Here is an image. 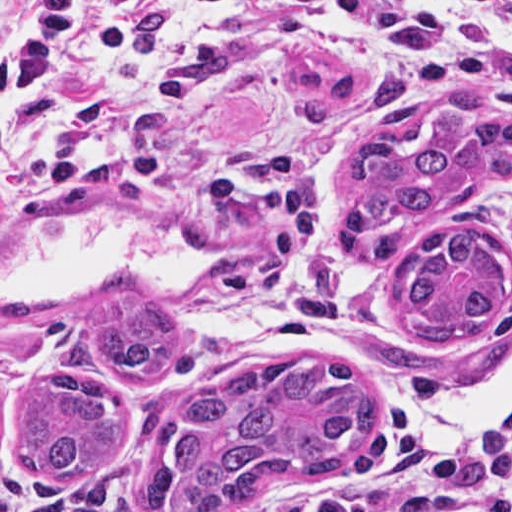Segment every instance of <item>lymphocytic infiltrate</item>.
<instances>
[{"mask_svg":"<svg viewBox=\"0 0 512 512\" xmlns=\"http://www.w3.org/2000/svg\"><path fill=\"white\" fill-rule=\"evenodd\" d=\"M460 1L512 27V2ZM249 7L312 40L351 44L391 74H440L464 94L512 102V55L411 0H25L0 29L1 89L59 99L88 92L100 33L134 76L37 166L0 165V210L52 204L84 180L170 188L200 206L261 218L290 248L315 255L329 202L313 162L276 155L251 165L218 153L170 159L147 143L148 114L192 109L227 66L214 39L176 46L168 83L150 79L149 57L193 23ZM288 512H512V409L451 415L410 401L377 428L345 483Z\"/></svg>","mask_w":512,"mask_h":512,"instance_id":"1","label":"lymphocytic infiltrate"}]
</instances>
